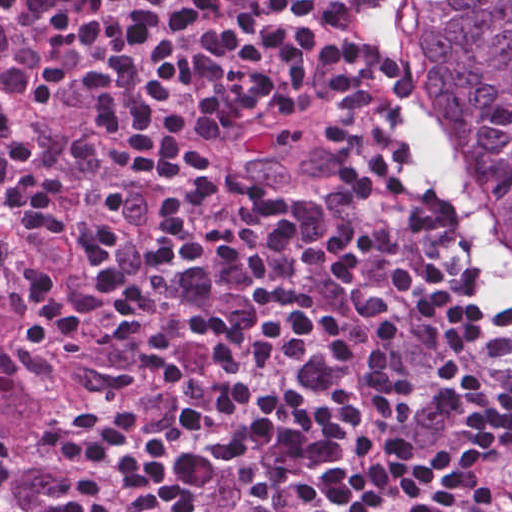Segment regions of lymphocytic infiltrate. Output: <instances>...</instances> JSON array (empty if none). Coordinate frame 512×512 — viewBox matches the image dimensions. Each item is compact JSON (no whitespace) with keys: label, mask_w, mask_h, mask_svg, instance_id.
I'll list each match as a JSON object with an SVG mask.
<instances>
[{"label":"lymphocytic infiltrate","mask_w":512,"mask_h":512,"mask_svg":"<svg viewBox=\"0 0 512 512\" xmlns=\"http://www.w3.org/2000/svg\"><path fill=\"white\" fill-rule=\"evenodd\" d=\"M31 5L0 197L92 374L49 509L512 512V306L379 0Z\"/></svg>","instance_id":"1"}]
</instances>
